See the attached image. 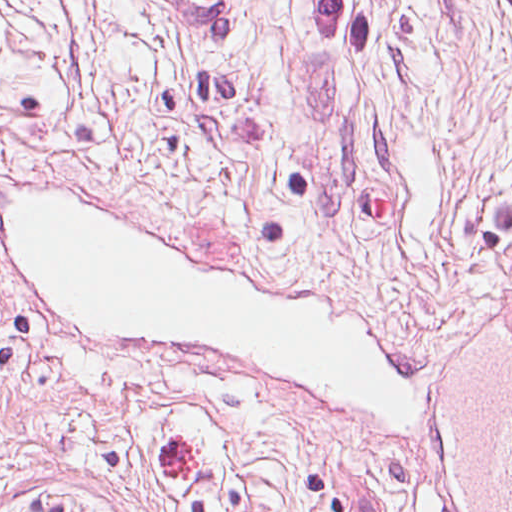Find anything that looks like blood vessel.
<instances>
[{
	"label": "blood vessel",
	"instance_id": "obj_1",
	"mask_svg": "<svg viewBox=\"0 0 512 512\" xmlns=\"http://www.w3.org/2000/svg\"><path fill=\"white\" fill-rule=\"evenodd\" d=\"M206 29H233L239 0H170ZM420 487L435 512H512V295L450 334L423 417Z\"/></svg>",
	"mask_w": 512,
	"mask_h": 512
}]
</instances>
